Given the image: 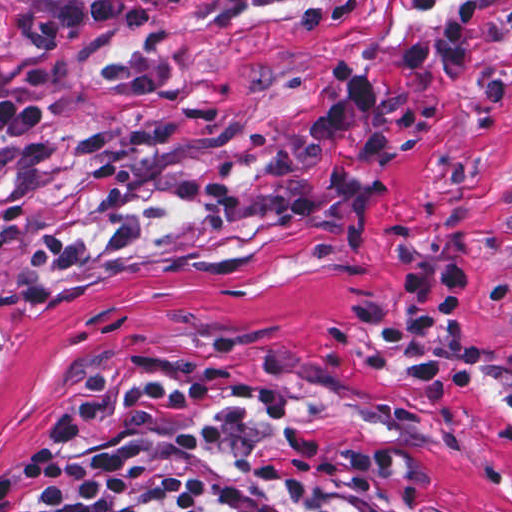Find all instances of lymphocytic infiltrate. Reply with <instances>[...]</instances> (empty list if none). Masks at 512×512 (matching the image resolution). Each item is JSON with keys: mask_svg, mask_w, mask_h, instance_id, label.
Returning <instances> with one entry per match:
<instances>
[{"mask_svg": "<svg viewBox=\"0 0 512 512\" xmlns=\"http://www.w3.org/2000/svg\"><path fill=\"white\" fill-rule=\"evenodd\" d=\"M207 24L229 27L253 5L289 0H194ZM163 18L142 0H59L35 8L27 36L0 49V137H26L54 122L11 82L5 57L42 60L88 35H133ZM408 74L476 77L475 0H449L396 53ZM334 92L312 113L333 201L309 198L291 158L260 166L252 184L209 171L166 183L170 202L194 203L221 231L254 216L275 233L337 246L362 240L378 193L344 152L375 168L393 147L373 123V71L333 61ZM401 310L371 304L352 320L378 350L407 362L411 387L442 405L479 369L477 351L448 345L446 327L477 269L448 254L426 258L393 245ZM0 512H454L420 494L399 442L395 403L367 383L270 345H209L117 363L37 447L0 476Z\"/></svg>", "mask_w": 512, "mask_h": 512, "instance_id": "obj_1", "label": "lymphocytic infiltrate"}]
</instances>
